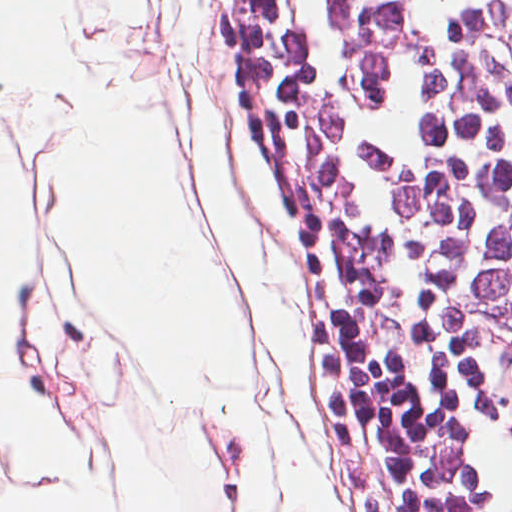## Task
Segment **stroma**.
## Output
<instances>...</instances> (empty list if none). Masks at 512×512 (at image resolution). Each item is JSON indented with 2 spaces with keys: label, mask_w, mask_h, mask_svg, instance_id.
I'll use <instances>...</instances> for the list:
<instances>
[{
  "label": "stroma",
  "mask_w": 512,
  "mask_h": 512,
  "mask_svg": "<svg viewBox=\"0 0 512 512\" xmlns=\"http://www.w3.org/2000/svg\"><path fill=\"white\" fill-rule=\"evenodd\" d=\"M296 279L303 296L300 356L307 368L316 434L283 392L294 417L293 456L310 479L340 493L341 512H424L384 387L345 350L331 325L324 285L305 260L304 240ZM274 402L270 394L258 512H295L279 465L284 447L270 417Z\"/></svg>",
  "instance_id": "1"
}]
</instances>
